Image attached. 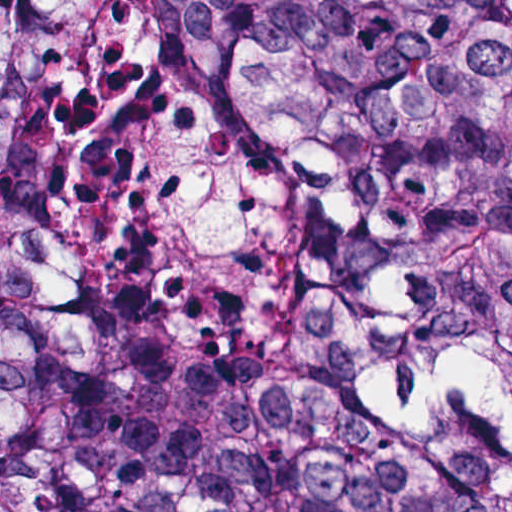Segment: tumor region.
I'll list each match as a JSON object with an SVG mask.
<instances>
[{
    "label": "tumor region",
    "mask_w": 512,
    "mask_h": 512,
    "mask_svg": "<svg viewBox=\"0 0 512 512\" xmlns=\"http://www.w3.org/2000/svg\"><path fill=\"white\" fill-rule=\"evenodd\" d=\"M0 512H512V0H0Z\"/></svg>",
    "instance_id": "tumor-region-1"
}]
</instances>
